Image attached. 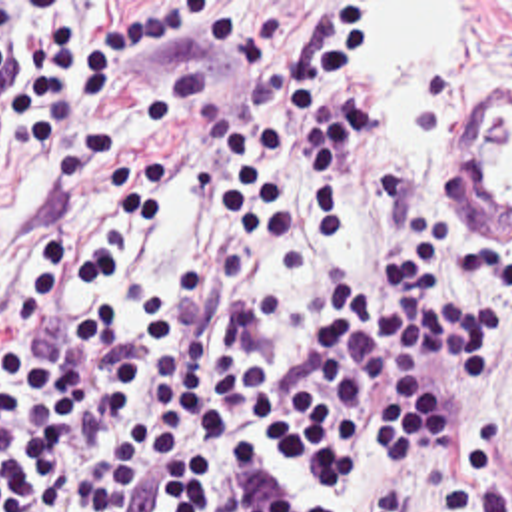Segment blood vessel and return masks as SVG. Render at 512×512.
Returning <instances> with one entry per match:
<instances>
[{
	"label": "blood vessel",
	"mask_w": 512,
	"mask_h": 512,
	"mask_svg": "<svg viewBox=\"0 0 512 512\" xmlns=\"http://www.w3.org/2000/svg\"><path fill=\"white\" fill-rule=\"evenodd\" d=\"M458 178L472 234L496 236L512 224V86L476 92Z\"/></svg>",
	"instance_id": "obj_1"
}]
</instances>
